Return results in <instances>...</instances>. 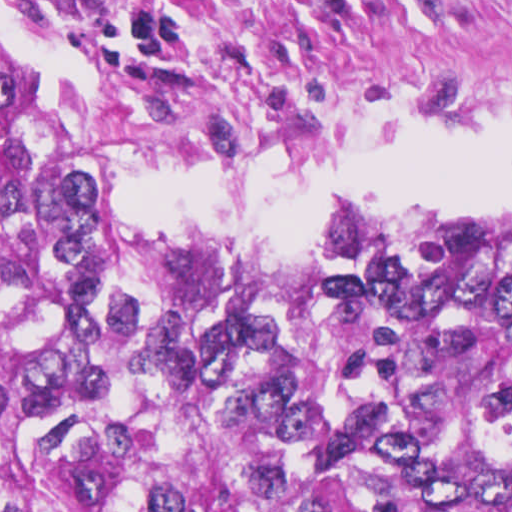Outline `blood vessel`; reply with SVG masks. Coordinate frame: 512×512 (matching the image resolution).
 <instances>
[{"label":"blood vessel","instance_id":"1","mask_svg":"<svg viewBox=\"0 0 512 512\" xmlns=\"http://www.w3.org/2000/svg\"><path fill=\"white\" fill-rule=\"evenodd\" d=\"M83 24L124 34L141 27L175 0H61Z\"/></svg>","mask_w":512,"mask_h":512}]
</instances>
